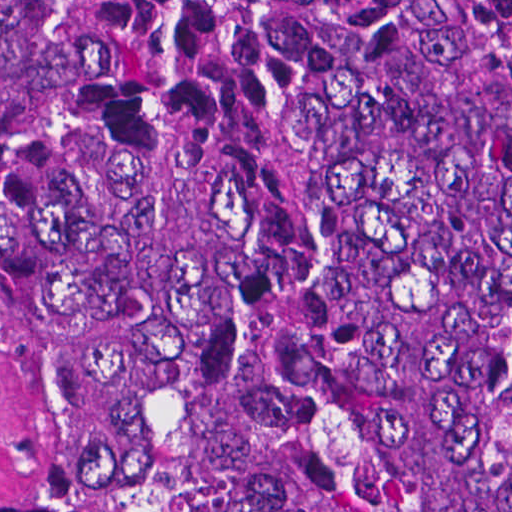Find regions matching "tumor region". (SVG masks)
I'll list each match as a JSON object with an SVG mask.
<instances>
[{"instance_id":"tumor-region-1","label":"tumor region","mask_w":512,"mask_h":512,"mask_svg":"<svg viewBox=\"0 0 512 512\" xmlns=\"http://www.w3.org/2000/svg\"><path fill=\"white\" fill-rule=\"evenodd\" d=\"M0 512H512V1H0Z\"/></svg>"}]
</instances>
